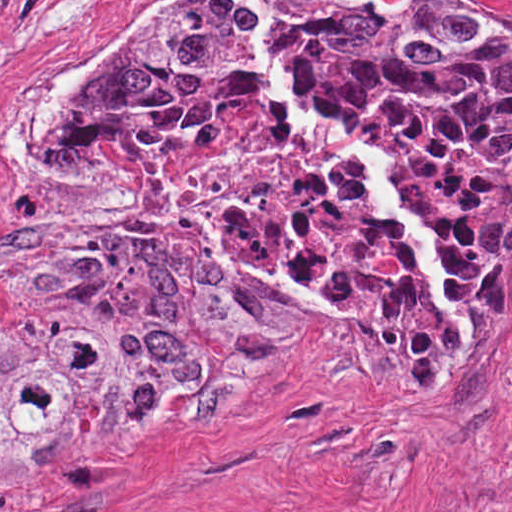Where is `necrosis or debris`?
Segmentation results:
<instances>
[{"instance_id":"1","label":"necrosis or debris","mask_w":512,"mask_h":512,"mask_svg":"<svg viewBox=\"0 0 512 512\" xmlns=\"http://www.w3.org/2000/svg\"><path fill=\"white\" fill-rule=\"evenodd\" d=\"M46 0H0V127L42 31ZM352 138L377 149L399 192L438 220L455 259L503 181L443 130L378 108ZM34 218L76 236H145L233 276L292 285L309 304L371 316L398 262L397 227L354 165L254 97L170 140L71 139L33 196Z\"/></svg>"}]
</instances>
